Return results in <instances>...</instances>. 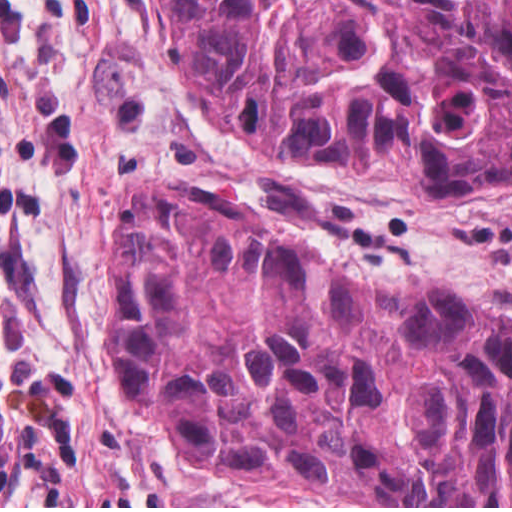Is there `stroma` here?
I'll return each instance as SVG.
<instances>
[{
  "mask_svg": "<svg viewBox=\"0 0 512 512\" xmlns=\"http://www.w3.org/2000/svg\"><path fill=\"white\" fill-rule=\"evenodd\" d=\"M140 181L230 197L355 282L434 281L512 316V193L429 196L410 169L305 166L226 140L171 70L150 0H0V205L105 388L106 232ZM116 407L174 508L235 476L199 475L149 415Z\"/></svg>",
  "mask_w": 512,
  "mask_h": 512,
  "instance_id": "stroma-1",
  "label": "stroma"
}]
</instances>
